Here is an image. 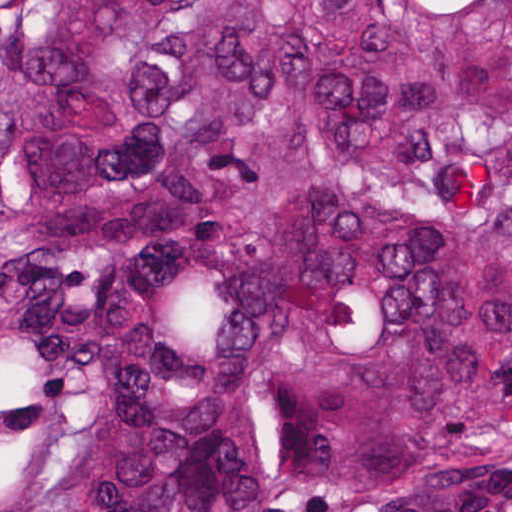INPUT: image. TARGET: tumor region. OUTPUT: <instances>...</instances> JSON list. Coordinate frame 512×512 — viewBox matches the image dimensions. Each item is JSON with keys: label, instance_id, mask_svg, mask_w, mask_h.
<instances>
[{"label": "tumor region", "instance_id": "1", "mask_svg": "<svg viewBox=\"0 0 512 512\" xmlns=\"http://www.w3.org/2000/svg\"><path fill=\"white\" fill-rule=\"evenodd\" d=\"M512 426V0H0V512H336Z\"/></svg>", "mask_w": 512, "mask_h": 512}]
</instances>
